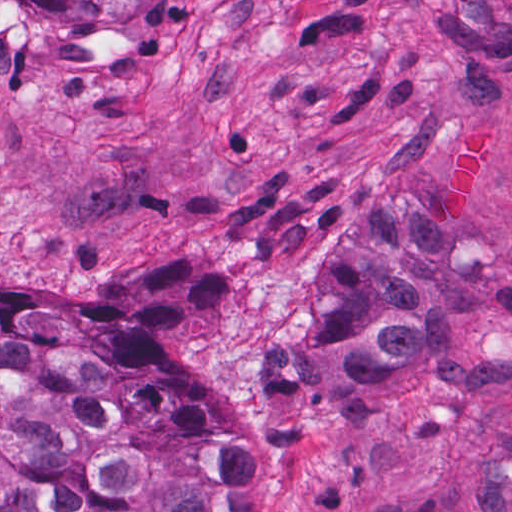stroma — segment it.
<instances>
[{"mask_svg": "<svg viewBox=\"0 0 512 512\" xmlns=\"http://www.w3.org/2000/svg\"><path fill=\"white\" fill-rule=\"evenodd\" d=\"M355 195L422 210L505 311L495 349L402 400L243 426L309 333ZM148 264L228 282L133 339L194 378L247 448L256 512H512V0H179L59 48L0 0V289L133 293Z\"/></svg>", "mask_w": 512, "mask_h": 512, "instance_id": "1", "label": "stroma"}]
</instances>
